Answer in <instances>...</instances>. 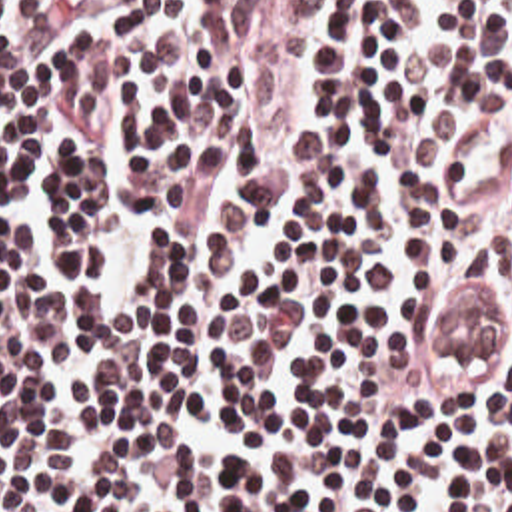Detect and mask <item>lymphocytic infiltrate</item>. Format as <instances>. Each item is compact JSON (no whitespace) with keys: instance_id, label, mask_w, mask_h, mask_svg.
<instances>
[{"instance_id":"obj_1","label":"lymphocytic infiltrate","mask_w":512,"mask_h":512,"mask_svg":"<svg viewBox=\"0 0 512 512\" xmlns=\"http://www.w3.org/2000/svg\"><path fill=\"white\" fill-rule=\"evenodd\" d=\"M0 512H512V0H0Z\"/></svg>"}]
</instances>
